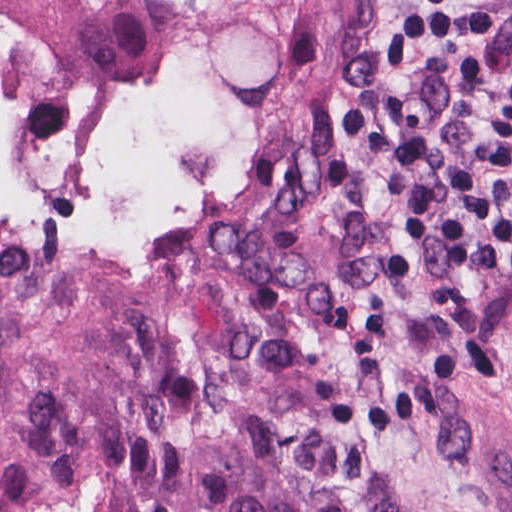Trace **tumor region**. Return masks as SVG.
<instances>
[{"instance_id": "1", "label": "tumor region", "mask_w": 512, "mask_h": 512, "mask_svg": "<svg viewBox=\"0 0 512 512\" xmlns=\"http://www.w3.org/2000/svg\"><path fill=\"white\" fill-rule=\"evenodd\" d=\"M203 0H0V74L143 92ZM378 156L0 97V512H512L327 325L274 234L197 228ZM143 229H186L112 240Z\"/></svg>"}]
</instances>
